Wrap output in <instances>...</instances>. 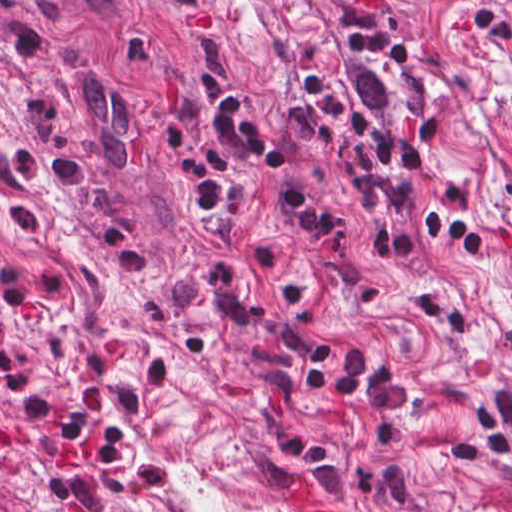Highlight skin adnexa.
<instances>
[{
    "label": "skin adnexa",
    "mask_w": 512,
    "mask_h": 512,
    "mask_svg": "<svg viewBox=\"0 0 512 512\" xmlns=\"http://www.w3.org/2000/svg\"><path fill=\"white\" fill-rule=\"evenodd\" d=\"M0 512H35L20 496L0 481Z\"/></svg>",
    "instance_id": "1"
}]
</instances>
